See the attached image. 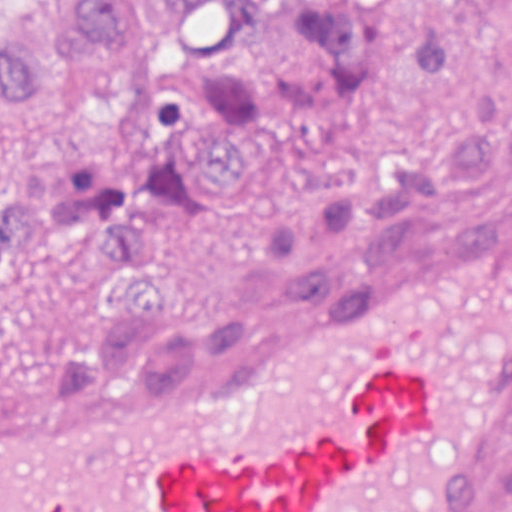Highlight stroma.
<instances>
[{
  "mask_svg": "<svg viewBox=\"0 0 512 512\" xmlns=\"http://www.w3.org/2000/svg\"><path fill=\"white\" fill-rule=\"evenodd\" d=\"M94 162L108 170L105 145L94 121L45 106L43 112L5 116L0 128V202H7L19 173L41 166L58 174L72 164ZM110 171V170H109ZM313 179V152L245 158V186L225 199V212L208 229L184 239L171 267L166 321L205 323L223 311L267 222L301 204ZM442 224L421 228L393 262L363 266L341 261L338 279L381 274L419 254L512 219V176L485 193L437 212ZM97 309L68 288L30 289L0 309V377L31 358L77 350ZM512 450V433L486 469L466 512H473L481 485Z\"/></svg>",
  "mask_w": 512,
  "mask_h": 512,
  "instance_id": "stroma-1",
  "label": "stroma"
}]
</instances>
